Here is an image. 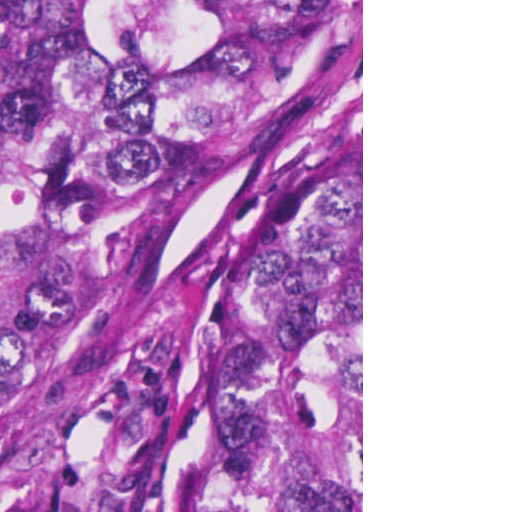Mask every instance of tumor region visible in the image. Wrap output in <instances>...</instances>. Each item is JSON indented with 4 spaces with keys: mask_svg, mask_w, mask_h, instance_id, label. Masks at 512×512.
Returning a JSON list of instances; mask_svg holds the SVG:
<instances>
[{
    "mask_svg": "<svg viewBox=\"0 0 512 512\" xmlns=\"http://www.w3.org/2000/svg\"><path fill=\"white\" fill-rule=\"evenodd\" d=\"M325 2L0 0V317L59 217L214 171ZM185 512H361V149L241 282Z\"/></svg>",
    "mask_w": 512,
    "mask_h": 512,
    "instance_id": "tumor-region-1",
    "label": "tumor region"
}]
</instances>
